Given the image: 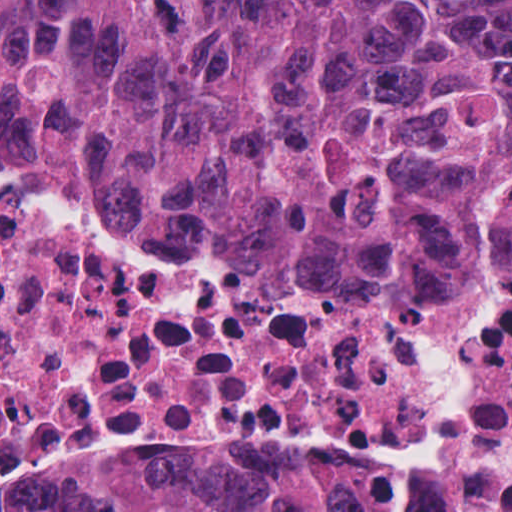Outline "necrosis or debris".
I'll use <instances>...</instances> for the list:
<instances>
[{
    "instance_id": "necrosis-or-debris-1",
    "label": "necrosis or debris",
    "mask_w": 512,
    "mask_h": 512,
    "mask_svg": "<svg viewBox=\"0 0 512 512\" xmlns=\"http://www.w3.org/2000/svg\"><path fill=\"white\" fill-rule=\"evenodd\" d=\"M325 440L356 512H512V240L432 274L216 246L0 159V512Z\"/></svg>"
}]
</instances>
